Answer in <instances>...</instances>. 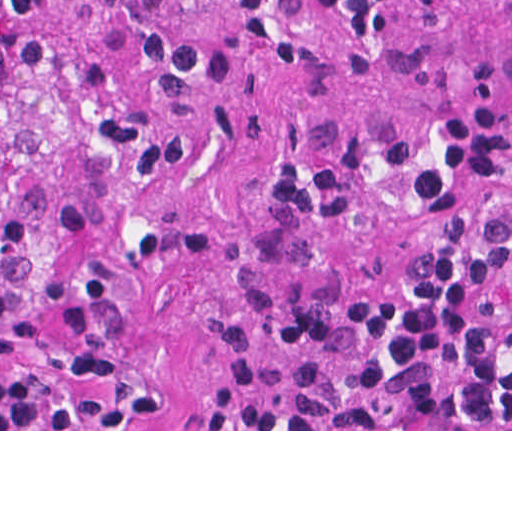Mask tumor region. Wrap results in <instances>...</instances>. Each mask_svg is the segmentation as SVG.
Returning a JSON list of instances; mask_svg holds the SVG:
<instances>
[{
    "mask_svg": "<svg viewBox=\"0 0 512 512\" xmlns=\"http://www.w3.org/2000/svg\"><path fill=\"white\" fill-rule=\"evenodd\" d=\"M221 0H0V429H63L164 269Z\"/></svg>",
    "mask_w": 512,
    "mask_h": 512,
    "instance_id": "obj_1",
    "label": "tumor region"
}]
</instances>
